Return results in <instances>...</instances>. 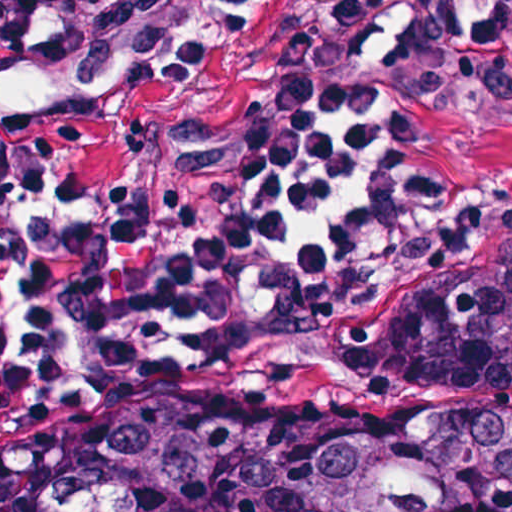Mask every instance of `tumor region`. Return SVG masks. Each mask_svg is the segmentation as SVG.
Returning <instances> with one entry per match:
<instances>
[{"mask_svg": "<svg viewBox=\"0 0 512 512\" xmlns=\"http://www.w3.org/2000/svg\"><path fill=\"white\" fill-rule=\"evenodd\" d=\"M29 45L87 83L92 109L209 58L140 51L94 62ZM335 112H360L390 138L368 232L421 215L434 190L404 176L413 130L377 99L333 91L291 93L240 122L153 127L134 177L95 187L74 173L75 183L99 201H190L249 171L294 124ZM340 333L391 406L243 423L223 377L117 425L67 434L57 512H512V238L382 300ZM174 347L115 346L85 368ZM35 443L0 453V512Z\"/></svg>", "mask_w": 512, "mask_h": 512, "instance_id": "1", "label": "tumor region"}]
</instances>
